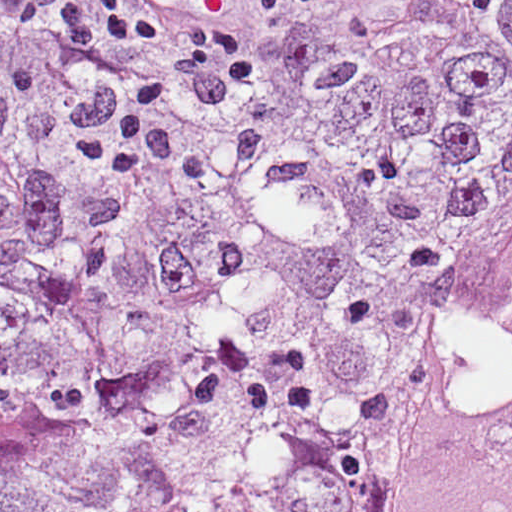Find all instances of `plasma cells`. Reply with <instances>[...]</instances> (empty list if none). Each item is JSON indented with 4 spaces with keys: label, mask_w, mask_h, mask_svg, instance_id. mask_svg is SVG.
Here are the masks:
<instances>
[{
    "label": "plasma cells",
    "mask_w": 512,
    "mask_h": 512,
    "mask_svg": "<svg viewBox=\"0 0 512 512\" xmlns=\"http://www.w3.org/2000/svg\"><path fill=\"white\" fill-rule=\"evenodd\" d=\"M44 0H13V13L17 21H22L36 9Z\"/></svg>",
    "instance_id": "9512152a"
}]
</instances>
